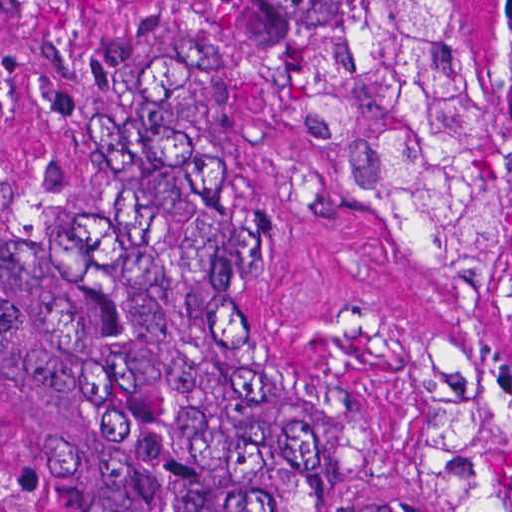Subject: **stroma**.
I'll list each match as a JSON object with an SVG mask.
<instances>
[{
  "label": "stroma",
  "instance_id": "35a3bbf8",
  "mask_svg": "<svg viewBox=\"0 0 512 512\" xmlns=\"http://www.w3.org/2000/svg\"><path fill=\"white\" fill-rule=\"evenodd\" d=\"M475 107L496 111V0H453ZM173 72L226 180L265 312L330 449L372 512H443L439 340L512 364V238L478 292L411 278L333 179L340 133L286 95L212 0H0V133L57 188H96L134 80ZM0 512H61L0 448Z\"/></svg>",
  "mask_w": 512,
  "mask_h": 512
}]
</instances>
